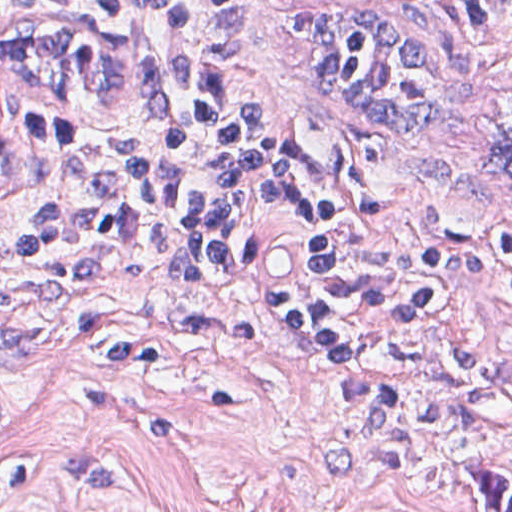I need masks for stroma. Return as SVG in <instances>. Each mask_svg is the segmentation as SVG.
I'll list each match as a JSON object with an SVG mask.
<instances>
[{
    "instance_id": "1",
    "label": "stroma",
    "mask_w": 512,
    "mask_h": 512,
    "mask_svg": "<svg viewBox=\"0 0 512 512\" xmlns=\"http://www.w3.org/2000/svg\"><path fill=\"white\" fill-rule=\"evenodd\" d=\"M333 2L447 43L455 87L421 142L344 126L299 90L281 30ZM78 22L134 37V104L0 90V130L63 118L118 136L158 126L155 41L83 0H0V23ZM237 109L302 161L367 171L415 225L512 259V32L454 0H282L230 70ZM512 478V318L446 305L354 362L263 342L179 297L115 245L38 249L0 231V512H486L464 466Z\"/></svg>"
}]
</instances>
